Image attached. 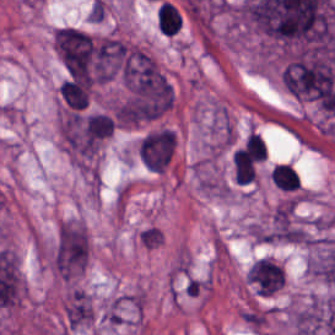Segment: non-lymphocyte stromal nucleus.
<instances>
[{"mask_svg":"<svg viewBox=\"0 0 335 335\" xmlns=\"http://www.w3.org/2000/svg\"><path fill=\"white\" fill-rule=\"evenodd\" d=\"M92 317V307L87 293L79 288H72L64 305V319L67 327L78 329L88 325Z\"/></svg>","mask_w":335,"mask_h":335,"instance_id":"obj_1","label":"non-lymphocyte stromal nucleus"}]
</instances>
